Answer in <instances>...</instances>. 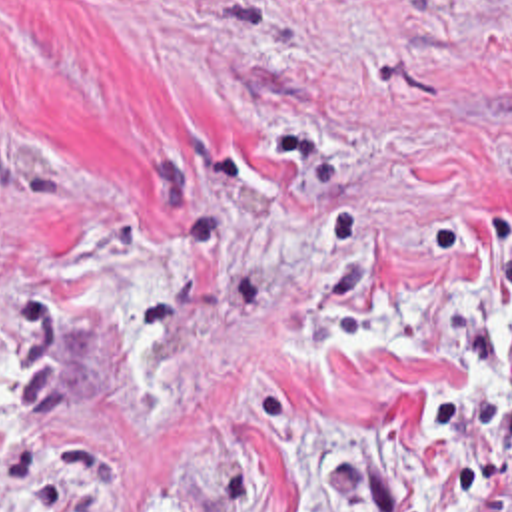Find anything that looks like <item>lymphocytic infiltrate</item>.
Here are the masks:
<instances>
[{
	"label": "lymphocytic infiltrate",
	"mask_w": 512,
	"mask_h": 512,
	"mask_svg": "<svg viewBox=\"0 0 512 512\" xmlns=\"http://www.w3.org/2000/svg\"><path fill=\"white\" fill-rule=\"evenodd\" d=\"M402 470L424 512H506L512 480V250L458 252L446 362L406 416Z\"/></svg>",
	"instance_id": "f902f5d3"
}]
</instances>
